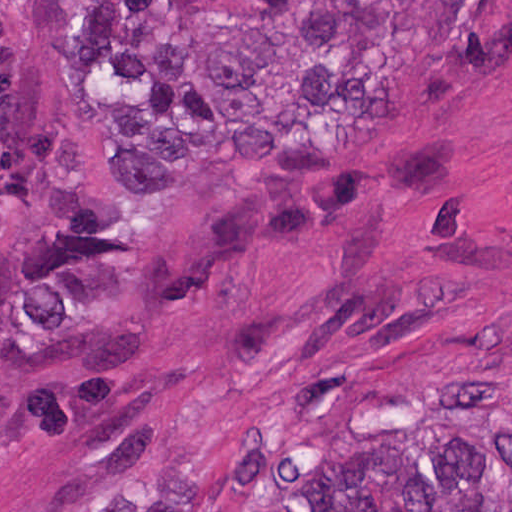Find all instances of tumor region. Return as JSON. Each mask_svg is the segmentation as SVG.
<instances>
[{
  "label": "tumor region",
  "mask_w": 512,
  "mask_h": 512,
  "mask_svg": "<svg viewBox=\"0 0 512 512\" xmlns=\"http://www.w3.org/2000/svg\"><path fill=\"white\" fill-rule=\"evenodd\" d=\"M29 26L109 179L167 194L325 153L410 85L436 101L487 60L492 0H33ZM249 512H512V390L326 428Z\"/></svg>",
  "instance_id": "e687c5a6"
}]
</instances>
